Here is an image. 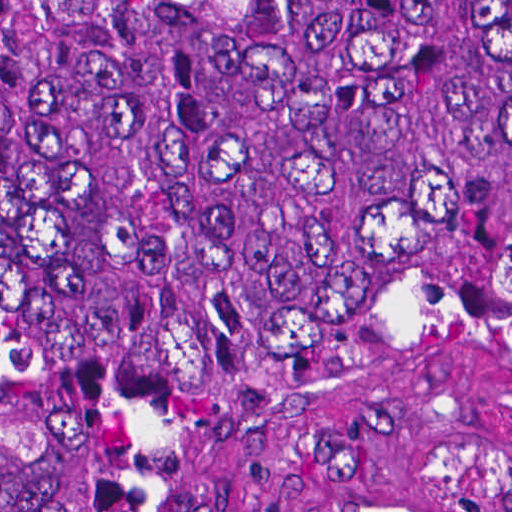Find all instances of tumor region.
I'll use <instances>...</instances> for the list:
<instances>
[{
  "label": "tumor region",
  "instance_id": "1",
  "mask_svg": "<svg viewBox=\"0 0 512 512\" xmlns=\"http://www.w3.org/2000/svg\"><path fill=\"white\" fill-rule=\"evenodd\" d=\"M321 393L512 401V1H0V512Z\"/></svg>",
  "mask_w": 512,
  "mask_h": 512
}]
</instances>
